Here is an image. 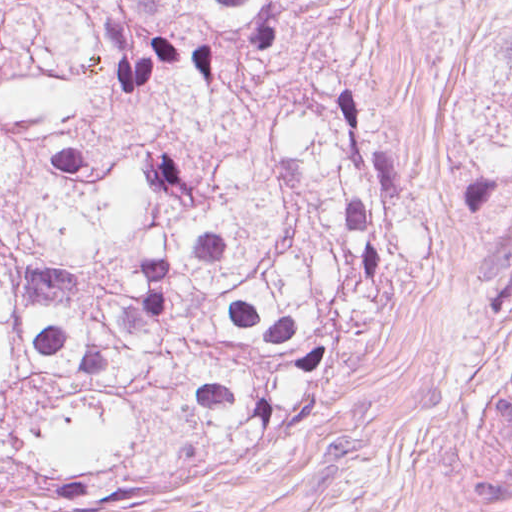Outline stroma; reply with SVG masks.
<instances>
[{
    "label": "stroma",
    "mask_w": 512,
    "mask_h": 512,
    "mask_svg": "<svg viewBox=\"0 0 512 512\" xmlns=\"http://www.w3.org/2000/svg\"><path fill=\"white\" fill-rule=\"evenodd\" d=\"M363 74L419 225L335 393L246 457L60 512H512V0L395 19Z\"/></svg>",
    "instance_id": "1"
}]
</instances>
